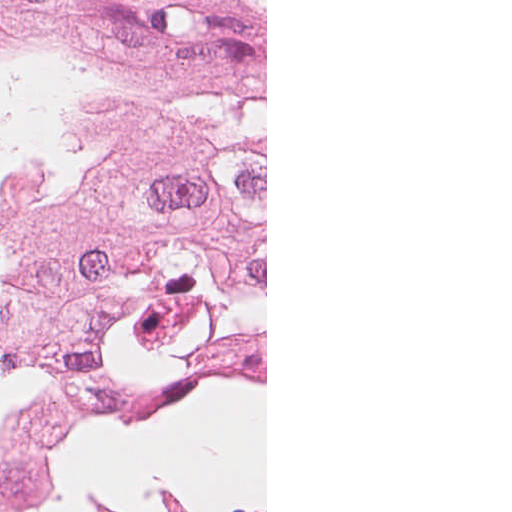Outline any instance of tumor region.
Instances as JSON below:
<instances>
[{
  "label": "tumor region",
  "mask_w": 512,
  "mask_h": 512,
  "mask_svg": "<svg viewBox=\"0 0 512 512\" xmlns=\"http://www.w3.org/2000/svg\"><path fill=\"white\" fill-rule=\"evenodd\" d=\"M52 0H0V242Z\"/></svg>",
  "instance_id": "tumor-region-1"
}]
</instances>
